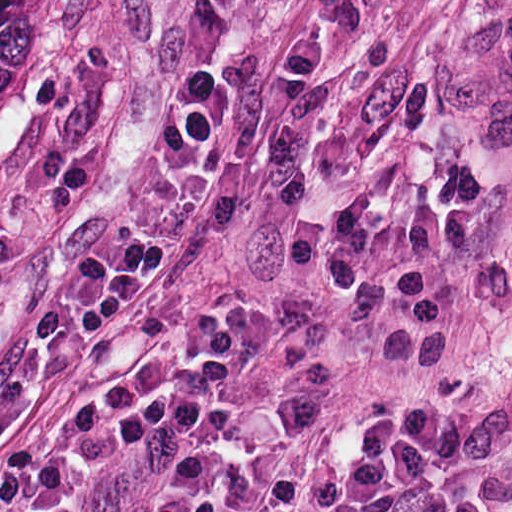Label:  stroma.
<instances>
[{
    "label": "stroma",
    "instance_id": "35a3bbf8",
    "mask_svg": "<svg viewBox=\"0 0 512 512\" xmlns=\"http://www.w3.org/2000/svg\"><path fill=\"white\" fill-rule=\"evenodd\" d=\"M426 2L63 0L44 123L0 146V364L45 271L145 229L188 76L228 78L238 104L178 239L53 365L0 460L119 366L191 362L199 314L236 305L256 340L203 512H262ZM165 458L146 443L97 512H138Z\"/></svg>",
    "mask_w": 512,
    "mask_h": 512
}]
</instances>
